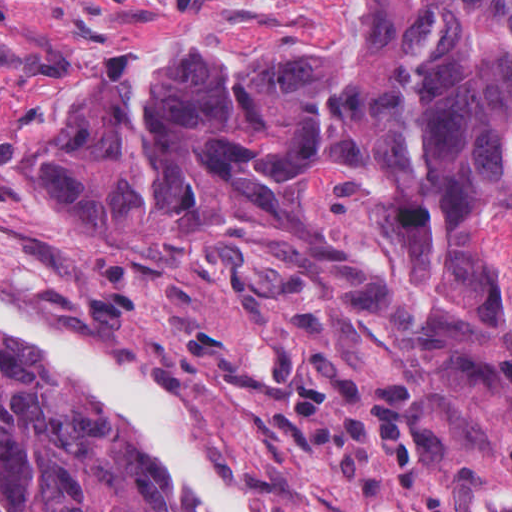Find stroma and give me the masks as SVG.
<instances>
[{"instance_id": "1", "label": "stroma", "mask_w": 512, "mask_h": 512, "mask_svg": "<svg viewBox=\"0 0 512 512\" xmlns=\"http://www.w3.org/2000/svg\"><path fill=\"white\" fill-rule=\"evenodd\" d=\"M146 0H0V298L136 370L179 410L242 512H476L512 494V186L463 231L494 286L482 320L448 308L419 256L308 186L322 241L381 291L332 295L237 202L91 236L38 187L89 74L128 43L233 67L303 24L367 37L380 0H206L149 23Z\"/></svg>"}]
</instances>
